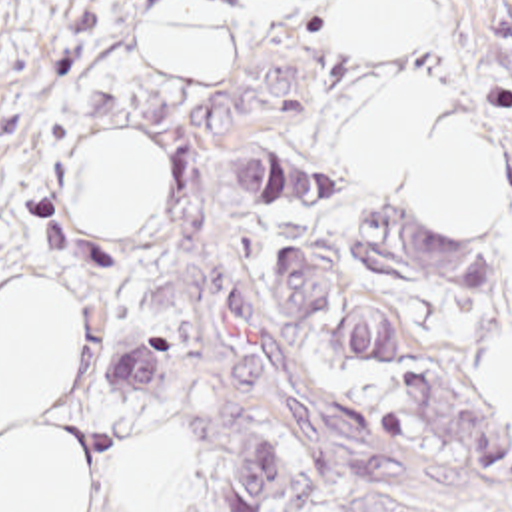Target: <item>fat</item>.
Returning <instances> with one entry per match:
<instances>
[{"label":"fat","mask_w":512,"mask_h":512,"mask_svg":"<svg viewBox=\"0 0 512 512\" xmlns=\"http://www.w3.org/2000/svg\"><path fill=\"white\" fill-rule=\"evenodd\" d=\"M338 44L400 50L436 36V0H336ZM145 50L175 80H217L229 52L225 0H165L145 24ZM344 166L368 186L452 218L504 216L502 156L482 116L454 92L414 80L344 126ZM65 204L91 226L153 216L167 158L129 136L81 140L65 166ZM81 364V318L43 278L0 296V512H91L87 447L53 415ZM476 396L512 410V342L468 370ZM127 512L187 509V463L177 437L131 459Z\"/></svg>","instance_id":"obj_1"}]
</instances>
